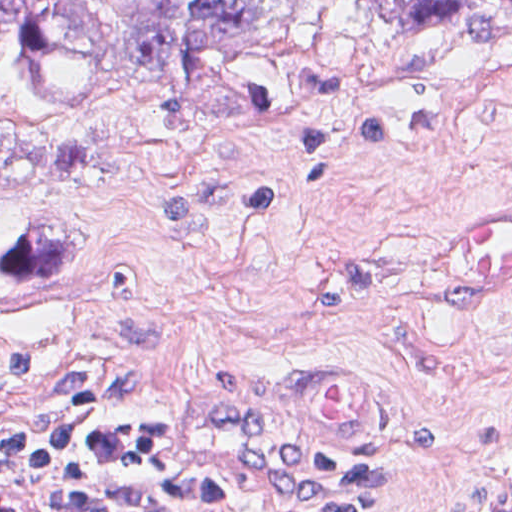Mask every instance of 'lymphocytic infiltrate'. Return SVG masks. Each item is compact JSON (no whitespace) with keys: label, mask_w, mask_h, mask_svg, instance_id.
Wrapping results in <instances>:
<instances>
[{"label":"lymphocytic infiltrate","mask_w":512,"mask_h":512,"mask_svg":"<svg viewBox=\"0 0 512 512\" xmlns=\"http://www.w3.org/2000/svg\"><path fill=\"white\" fill-rule=\"evenodd\" d=\"M302 467L331 491L288 512H371L383 485L368 463L307 456ZM1 467L40 478L56 512H265L216 476L169 420L144 419L81 393H63L40 426L1 429ZM490 512H512V485Z\"/></svg>","instance_id":"lymphocytic-infiltrate-1"}]
</instances>
